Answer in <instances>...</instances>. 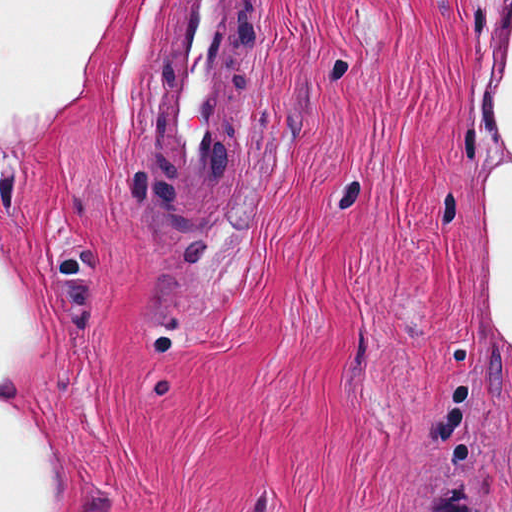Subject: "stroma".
<instances>
[{
    "mask_svg": "<svg viewBox=\"0 0 512 512\" xmlns=\"http://www.w3.org/2000/svg\"><path fill=\"white\" fill-rule=\"evenodd\" d=\"M178 4L123 0L54 125L0 143L74 512H512L477 300L512 0H251V168L205 234L148 197Z\"/></svg>",
    "mask_w": 512,
    "mask_h": 512,
    "instance_id": "stroma-1",
    "label": "stroma"
}]
</instances>
